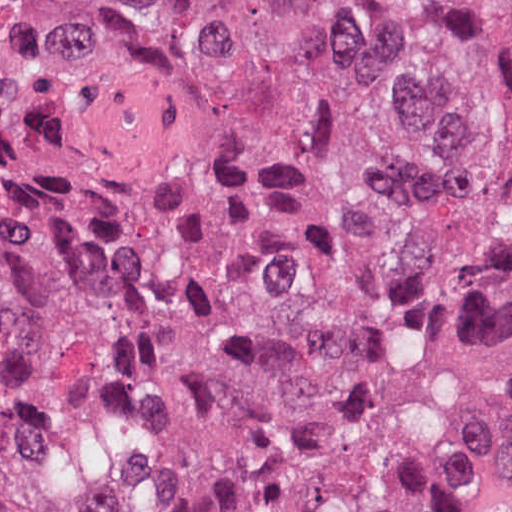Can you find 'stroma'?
Masks as SVG:
<instances>
[{"label": "stroma", "instance_id": "stroma-1", "mask_svg": "<svg viewBox=\"0 0 512 512\" xmlns=\"http://www.w3.org/2000/svg\"><path fill=\"white\" fill-rule=\"evenodd\" d=\"M461 506L460 512H512V484Z\"/></svg>", "mask_w": 512, "mask_h": 512}]
</instances>
